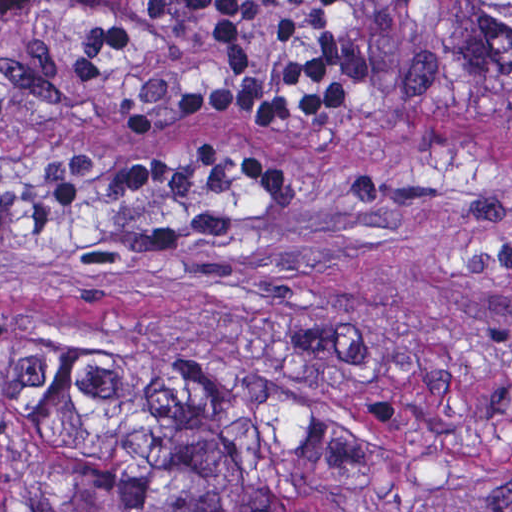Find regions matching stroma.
Wrapping results in <instances>:
<instances>
[{
  "label": "stroma",
  "instance_id": "stroma-1",
  "mask_svg": "<svg viewBox=\"0 0 512 512\" xmlns=\"http://www.w3.org/2000/svg\"><path fill=\"white\" fill-rule=\"evenodd\" d=\"M133 43L73 79L84 7H0V393L87 352L162 334L232 339L347 393L362 418L357 484L337 512H512V128L385 85L364 0L334 37L364 74L335 115L289 130L129 111L185 86L269 83L307 36L251 19L255 67L223 64L206 23L111 0ZM202 142L271 160L263 200L208 173L110 200L133 161Z\"/></svg>",
  "mask_w": 512,
  "mask_h": 512
}]
</instances>
